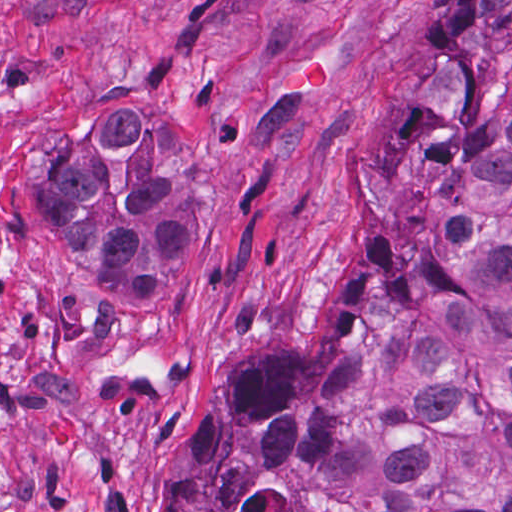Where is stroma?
Returning a JSON list of instances; mask_svg holds the SVG:
<instances>
[{
	"label": "stroma",
	"mask_w": 512,
	"mask_h": 512,
	"mask_svg": "<svg viewBox=\"0 0 512 512\" xmlns=\"http://www.w3.org/2000/svg\"><path fill=\"white\" fill-rule=\"evenodd\" d=\"M443 0H0V512H160L222 363L301 342L376 221ZM114 103L209 193L161 297L107 306L24 207Z\"/></svg>",
	"instance_id": "obj_1"
}]
</instances>
